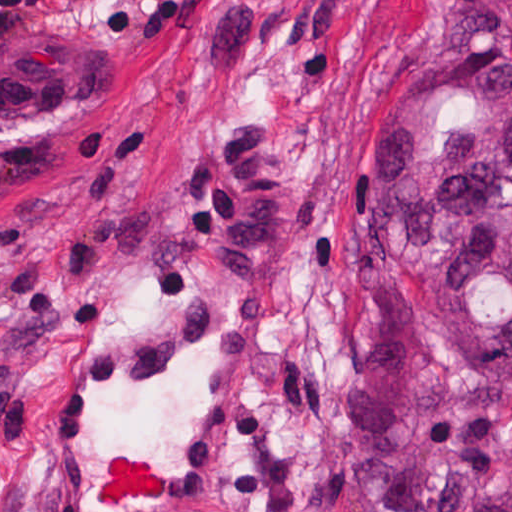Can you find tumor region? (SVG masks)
<instances>
[{"label":"tumor region","mask_w":512,"mask_h":512,"mask_svg":"<svg viewBox=\"0 0 512 512\" xmlns=\"http://www.w3.org/2000/svg\"><path fill=\"white\" fill-rule=\"evenodd\" d=\"M348 348L379 512H512V35L376 86L354 150Z\"/></svg>","instance_id":"obj_1"}]
</instances>
